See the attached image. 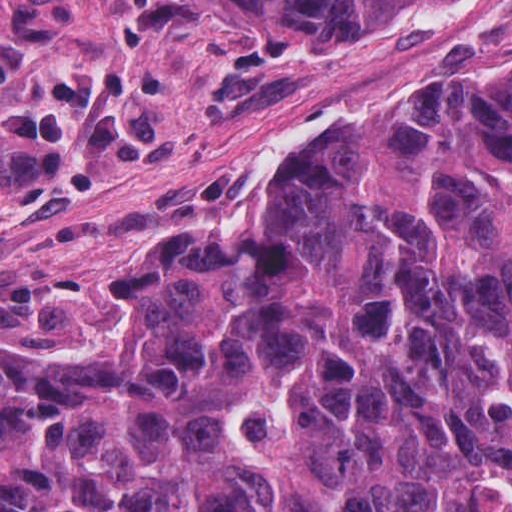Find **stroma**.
I'll list each match as a JSON object with an SVG mask.
<instances>
[{"label":"stroma","mask_w":512,"mask_h":512,"mask_svg":"<svg viewBox=\"0 0 512 512\" xmlns=\"http://www.w3.org/2000/svg\"><path fill=\"white\" fill-rule=\"evenodd\" d=\"M512 56V0L249 53L199 0H0L1 342L98 358L146 323L132 249L242 232L353 117Z\"/></svg>","instance_id":"stroma-1"}]
</instances>
